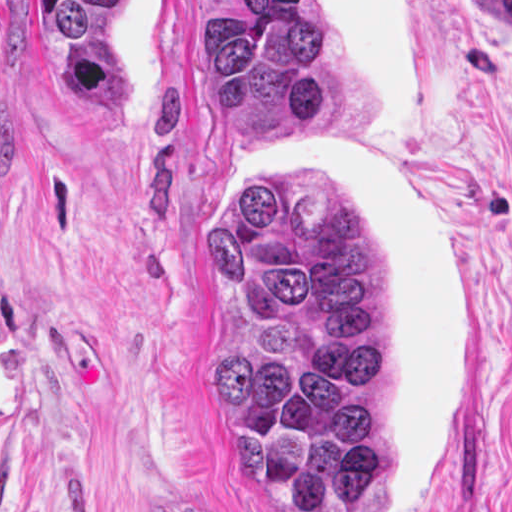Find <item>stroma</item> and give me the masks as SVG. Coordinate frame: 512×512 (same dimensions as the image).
<instances>
[{"label":"stroma","instance_id":"1","mask_svg":"<svg viewBox=\"0 0 512 512\" xmlns=\"http://www.w3.org/2000/svg\"><path fill=\"white\" fill-rule=\"evenodd\" d=\"M231 1H318L360 113L238 136L198 62ZM512 0H0V512H282L210 387L238 160L336 169L390 302L397 512H512Z\"/></svg>","mask_w":512,"mask_h":512}]
</instances>
